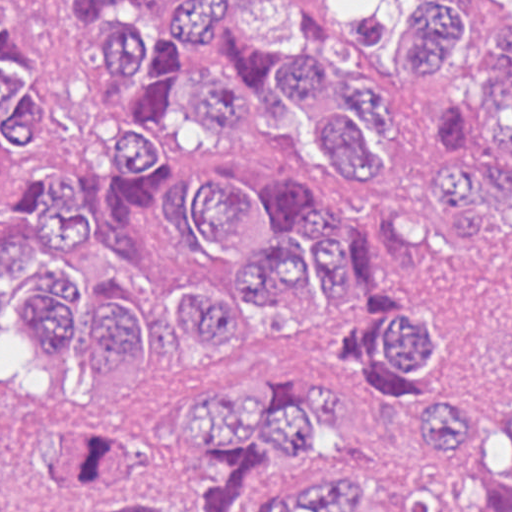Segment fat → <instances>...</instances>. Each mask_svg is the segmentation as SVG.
<instances>
[{"instance_id":"fat-1","label":"fat","mask_w":512,"mask_h":512,"mask_svg":"<svg viewBox=\"0 0 512 512\" xmlns=\"http://www.w3.org/2000/svg\"><path fill=\"white\" fill-rule=\"evenodd\" d=\"M1 383L24 402L60 398L62 371L33 346L30 326L1 327Z\"/></svg>"}]
</instances>
